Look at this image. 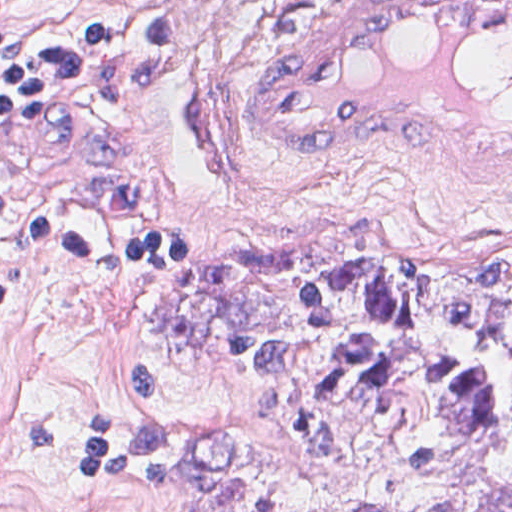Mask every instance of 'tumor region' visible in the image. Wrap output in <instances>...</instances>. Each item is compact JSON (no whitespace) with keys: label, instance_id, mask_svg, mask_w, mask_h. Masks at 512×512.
<instances>
[{"label":"tumor region","instance_id":"1","mask_svg":"<svg viewBox=\"0 0 512 512\" xmlns=\"http://www.w3.org/2000/svg\"><path fill=\"white\" fill-rule=\"evenodd\" d=\"M293 3L284 2L272 29ZM146 317L171 341L207 326L237 334L294 319L448 320L480 329L512 358V262L481 274L369 271L334 248L285 245L159 284ZM213 349L265 380L256 402L266 423L289 425L308 454L393 494L487 447L500 426L494 366L473 351L345 332L280 342L236 335ZM445 512H512V468Z\"/></svg>","mask_w":512,"mask_h":512}]
</instances>
